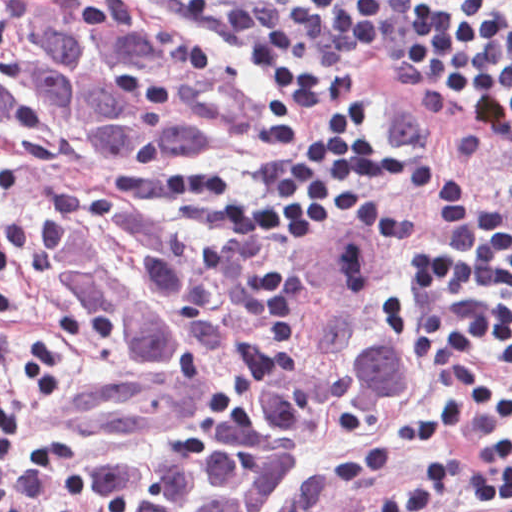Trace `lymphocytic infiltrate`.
Listing matches in <instances>:
<instances>
[{
    "instance_id": "lymphocytic-infiltrate-1",
    "label": "lymphocytic infiltrate",
    "mask_w": 512,
    "mask_h": 512,
    "mask_svg": "<svg viewBox=\"0 0 512 512\" xmlns=\"http://www.w3.org/2000/svg\"><path fill=\"white\" fill-rule=\"evenodd\" d=\"M147 1L222 28L284 98L329 105L306 126L278 103L256 202L219 179L171 174L175 203L229 236L306 243L356 221L369 191L409 197L376 218L397 246L436 382L463 404L431 403L389 425L327 474V494L349 496L389 458L463 436L481 457L464 496L512 512V208L488 183L396 150L385 102L353 93L377 45L399 71L445 81L459 116L512 147V15L474 0ZM452 472L434 462L368 512H419Z\"/></svg>"
}]
</instances>
